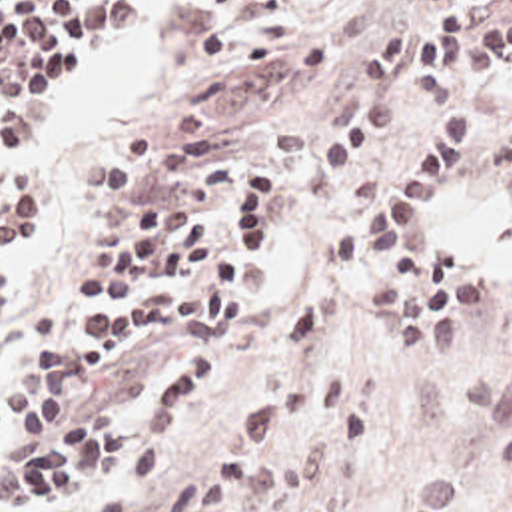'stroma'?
<instances>
[{
  "label": "stroma",
  "mask_w": 512,
  "mask_h": 512,
  "mask_svg": "<svg viewBox=\"0 0 512 512\" xmlns=\"http://www.w3.org/2000/svg\"><path fill=\"white\" fill-rule=\"evenodd\" d=\"M141 3V23L98 31L66 59L56 99L82 61L149 37V79L94 141L58 145L46 133L38 147L12 155L0 127V512H90L145 446L105 462L48 504L8 492L10 458L44 442L56 413L143 417L163 381L195 353L207 361V393L183 425L157 436L165 462L137 510L149 512L271 383L279 331L319 291L333 295V321L295 387L311 373L341 371L345 393L367 415V444L349 454L329 428L305 426L269 450L299 446L305 456L283 486L223 512H512V209L501 201L491 147L512 127V69L467 79L469 97L485 111V139L435 193L421 233L425 257L439 245L455 253L465 279L489 287V301L465 311L453 363L421 365V355L411 359L395 341L389 313L365 295L383 251L375 247L359 267L341 271L333 243L425 145L437 103L321 201L299 187V167L357 109L363 47L429 7L281 0L243 21L233 41L311 39L329 45V59L305 77H255L203 61L209 0ZM257 163L283 167V217L227 323L203 333L143 329L105 369H66V351L88 339L78 333L82 317L139 299L76 287L84 271L123 265L137 209L159 199L167 219L203 211L233 243L223 195L235 171Z\"/></svg>",
  "instance_id": "1"
}]
</instances>
